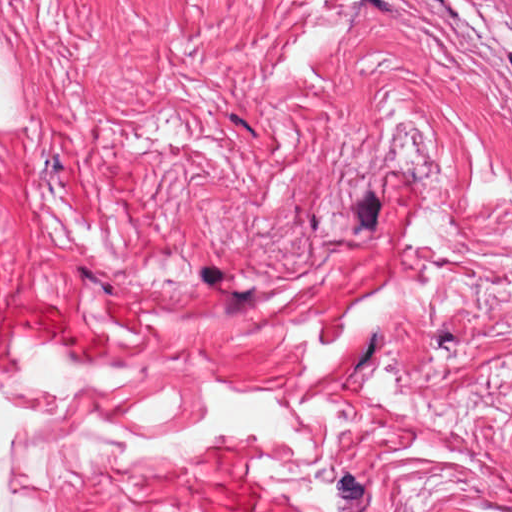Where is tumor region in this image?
Listing matches in <instances>:
<instances>
[{
  "label": "tumor region",
  "instance_id": "tumor-region-1",
  "mask_svg": "<svg viewBox=\"0 0 512 512\" xmlns=\"http://www.w3.org/2000/svg\"><path fill=\"white\" fill-rule=\"evenodd\" d=\"M476 1L485 10L512 16V0H476Z\"/></svg>",
  "mask_w": 512,
  "mask_h": 512
}]
</instances>
